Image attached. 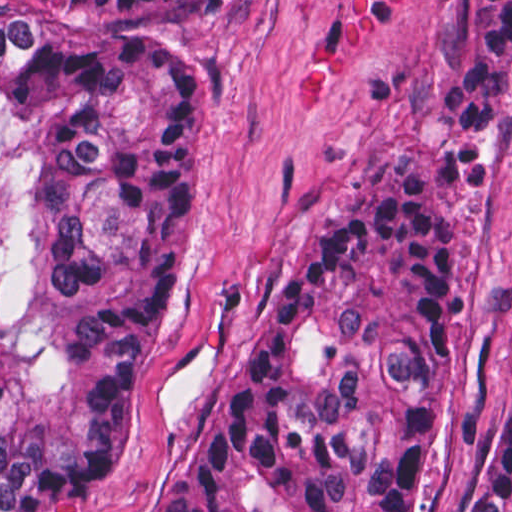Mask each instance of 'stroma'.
Wrapping results in <instances>:
<instances>
[{
	"mask_svg": "<svg viewBox=\"0 0 512 512\" xmlns=\"http://www.w3.org/2000/svg\"><path fill=\"white\" fill-rule=\"evenodd\" d=\"M218 1L172 30L199 87L204 154L179 289L123 471L42 512H144L232 374L272 292L362 188L399 167L452 201V344L429 481L411 512H462L512 389V73L491 190L459 174L442 88L473 1Z\"/></svg>",
	"mask_w": 512,
	"mask_h": 512,
	"instance_id": "obj_1",
	"label": "stroma"
}]
</instances>
